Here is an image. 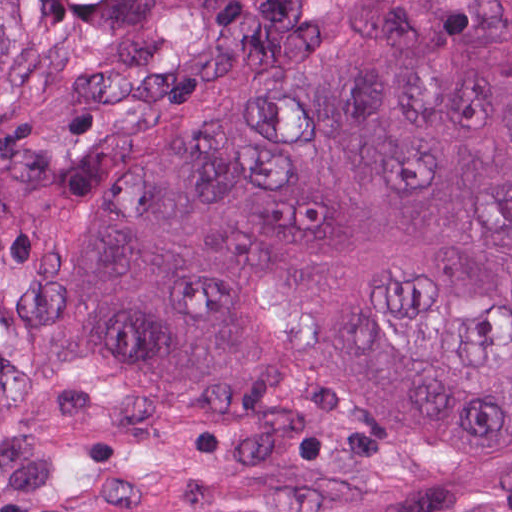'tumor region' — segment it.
<instances>
[{
  "label": "tumor region",
  "instance_id": "e687c5a6",
  "mask_svg": "<svg viewBox=\"0 0 512 512\" xmlns=\"http://www.w3.org/2000/svg\"><path fill=\"white\" fill-rule=\"evenodd\" d=\"M0 512H512V0H0Z\"/></svg>",
  "mask_w": 512,
  "mask_h": 512
}]
</instances>
